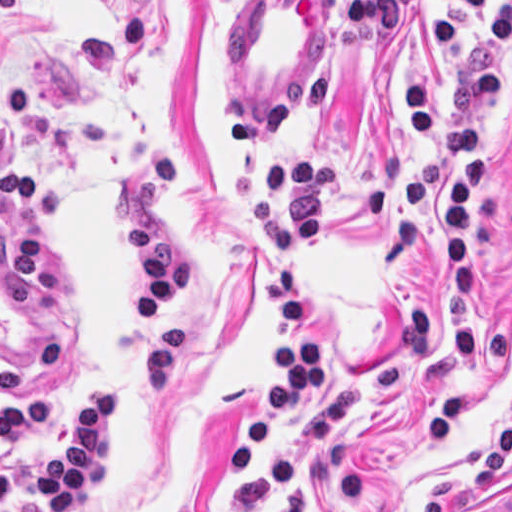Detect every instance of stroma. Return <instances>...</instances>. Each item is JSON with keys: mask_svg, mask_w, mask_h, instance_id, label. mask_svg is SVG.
I'll return each instance as SVG.
<instances>
[{"mask_svg": "<svg viewBox=\"0 0 512 512\" xmlns=\"http://www.w3.org/2000/svg\"><path fill=\"white\" fill-rule=\"evenodd\" d=\"M347 0H0V80L25 90L31 115L0 123V154L31 167L65 198V219L37 223L46 271L21 308L0 275V404L45 400L48 428L0 451L15 466L13 512H44L37 455L47 435L126 368L150 322L112 189L156 146L181 177L165 229L185 254L176 304L185 346L177 386L130 401L109 496L66 512H259L302 474L300 444L277 449L235 485L215 469L248 436L249 412L280 368L270 358L286 326L262 282L277 252L248 228L258 170L224 134L222 112H257L281 78L331 73L335 85L309 125L259 146L267 160H340L326 215V255L298 264L312 333L333 372L397 357L405 309L426 302L430 345L400 392L345 440L357 497L339 504L319 478L306 512H482L512 490V46L506 91L488 136L492 189L478 201L476 363L450 348V268L440 242V180L418 224L405 174L441 147L417 134L408 80L427 84L450 124V75L481 47L453 56L429 29L444 19L479 34L480 16L444 0H406L398 31L350 35ZM512 0H482L499 11ZM21 207L0 204L4 237L21 235ZM285 373V372H284ZM286 378L287 374L285 373Z\"/></svg>", "mask_w": 512, "mask_h": 512, "instance_id": "1", "label": "stroma"}]
</instances>
